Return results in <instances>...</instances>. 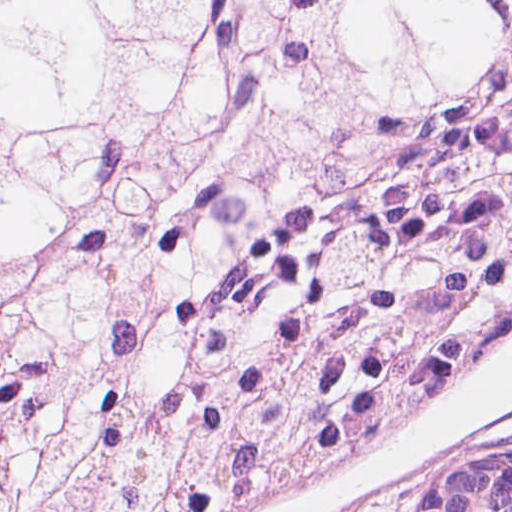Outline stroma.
Instances as JSON below:
<instances>
[{
	"instance_id": "stroma-1",
	"label": "stroma",
	"mask_w": 512,
	"mask_h": 512,
	"mask_svg": "<svg viewBox=\"0 0 512 512\" xmlns=\"http://www.w3.org/2000/svg\"><path fill=\"white\" fill-rule=\"evenodd\" d=\"M0 1H512V0H0ZM512 337V330L500 347ZM355 512H403L359 509Z\"/></svg>"
}]
</instances>
